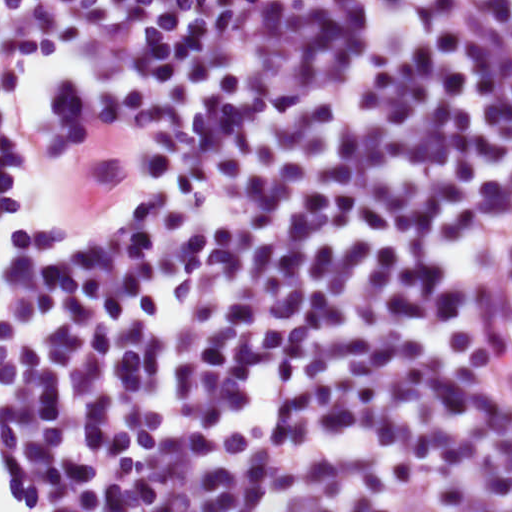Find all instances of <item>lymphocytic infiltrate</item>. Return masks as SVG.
<instances>
[{
    "instance_id": "obj_1",
    "label": "lymphocytic infiltrate",
    "mask_w": 512,
    "mask_h": 512,
    "mask_svg": "<svg viewBox=\"0 0 512 512\" xmlns=\"http://www.w3.org/2000/svg\"><path fill=\"white\" fill-rule=\"evenodd\" d=\"M0 512H512V0H0Z\"/></svg>"
}]
</instances>
